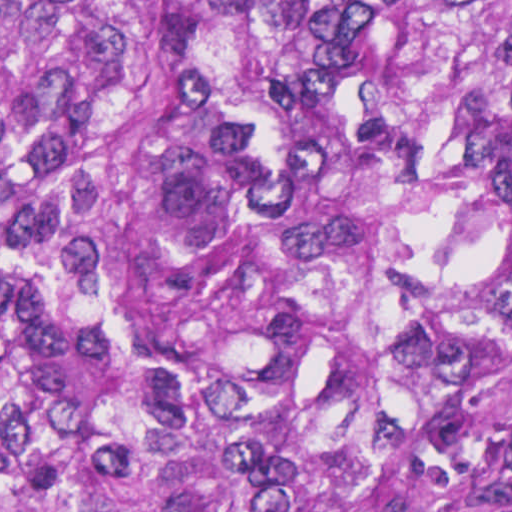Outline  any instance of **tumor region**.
Here are the masks:
<instances>
[{"mask_svg":"<svg viewBox=\"0 0 512 512\" xmlns=\"http://www.w3.org/2000/svg\"><path fill=\"white\" fill-rule=\"evenodd\" d=\"M0 512H512V0H0Z\"/></svg>","mask_w":512,"mask_h":512,"instance_id":"obj_1","label":"tumor region"}]
</instances>
